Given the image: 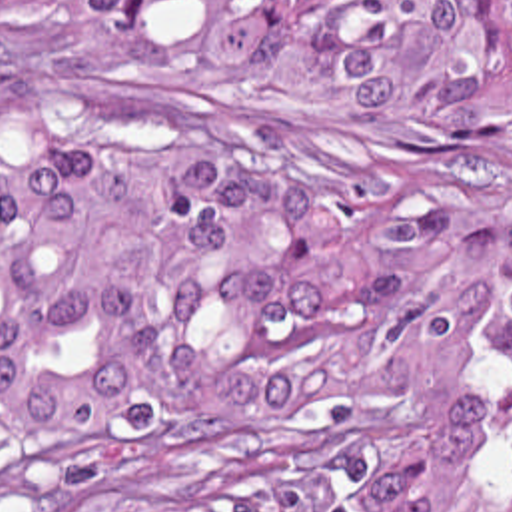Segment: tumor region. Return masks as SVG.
<instances>
[{"label":"tumor region","instance_id":"e687c5a6","mask_svg":"<svg viewBox=\"0 0 512 512\" xmlns=\"http://www.w3.org/2000/svg\"><path fill=\"white\" fill-rule=\"evenodd\" d=\"M0 512H512V0H0Z\"/></svg>","mask_w":512,"mask_h":512}]
</instances>
